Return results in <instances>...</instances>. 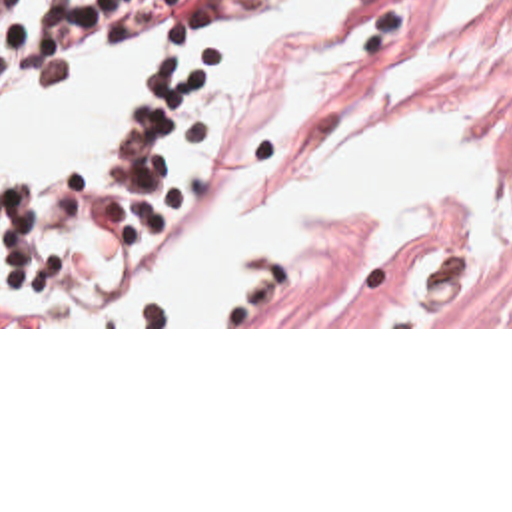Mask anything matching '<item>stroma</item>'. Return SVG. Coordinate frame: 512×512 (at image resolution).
<instances>
[{
  "label": "stroma",
  "instance_id": "stroma-1",
  "mask_svg": "<svg viewBox=\"0 0 512 512\" xmlns=\"http://www.w3.org/2000/svg\"><path fill=\"white\" fill-rule=\"evenodd\" d=\"M443 4L383 0L333 59L303 127L275 163L185 219L164 223V211L102 293L86 295L76 321L0 329H512V219L373 225L341 249L239 289L207 325H104L124 275L144 265L173 229L283 195L319 167L343 133L389 121H443L483 145H512V0H501L471 40L425 55ZM251 26L209 32V73L173 131V173L201 119L217 57Z\"/></svg>",
  "mask_w": 512,
  "mask_h": 512
}]
</instances>
